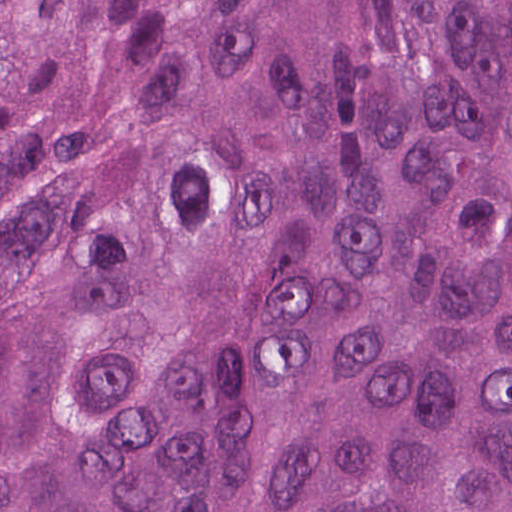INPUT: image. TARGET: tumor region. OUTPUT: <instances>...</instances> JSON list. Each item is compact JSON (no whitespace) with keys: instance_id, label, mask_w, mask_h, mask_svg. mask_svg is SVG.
<instances>
[{"instance_id":"tumor-region-1","label":"tumor region","mask_w":512,"mask_h":512,"mask_svg":"<svg viewBox=\"0 0 512 512\" xmlns=\"http://www.w3.org/2000/svg\"><path fill=\"white\" fill-rule=\"evenodd\" d=\"M0 512H512V0H0Z\"/></svg>"}]
</instances>
